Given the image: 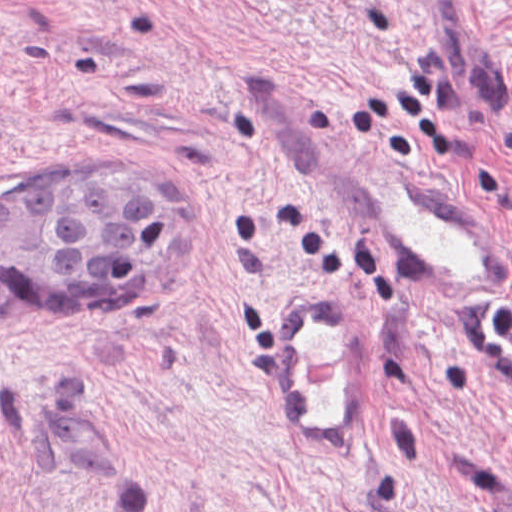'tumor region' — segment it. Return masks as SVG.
Wrapping results in <instances>:
<instances>
[{
  "label": "tumor region",
  "mask_w": 512,
  "mask_h": 512,
  "mask_svg": "<svg viewBox=\"0 0 512 512\" xmlns=\"http://www.w3.org/2000/svg\"><path fill=\"white\" fill-rule=\"evenodd\" d=\"M190 203L173 171L84 167L0 184V289L117 297L177 249Z\"/></svg>",
  "instance_id": "tumor-region-1"
}]
</instances>
